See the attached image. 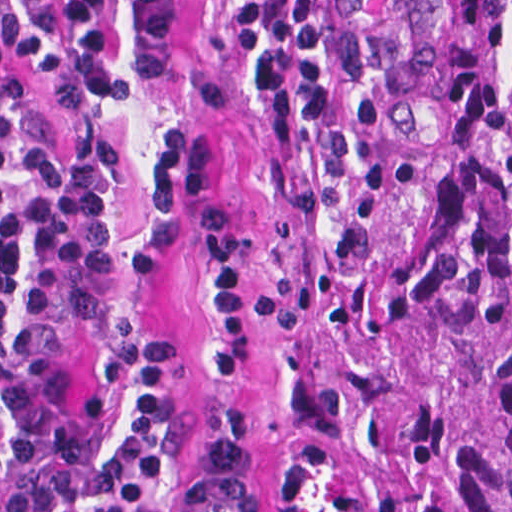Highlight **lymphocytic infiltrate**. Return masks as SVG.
Masks as SVG:
<instances>
[{
  "label": "lymphocytic infiltrate",
  "mask_w": 512,
  "mask_h": 512,
  "mask_svg": "<svg viewBox=\"0 0 512 512\" xmlns=\"http://www.w3.org/2000/svg\"><path fill=\"white\" fill-rule=\"evenodd\" d=\"M3 12L13 45L55 79L127 95L110 38V0H20ZM145 77L170 72L194 0H129ZM330 0H287L272 48L243 68L285 156L304 134L343 137V106L325 62ZM155 210L126 251L144 274L183 238L179 195L194 194L216 296L198 353L211 376L250 370L246 274L250 229L213 191L206 136L165 125L153 149ZM0 265L123 512H177L213 460V438L185 426L174 362L123 282L114 143L103 129L55 153L29 80L0 55ZM0 512H112L0 269Z\"/></svg>",
  "instance_id": "lymphocytic-infiltrate-1"
}]
</instances>
